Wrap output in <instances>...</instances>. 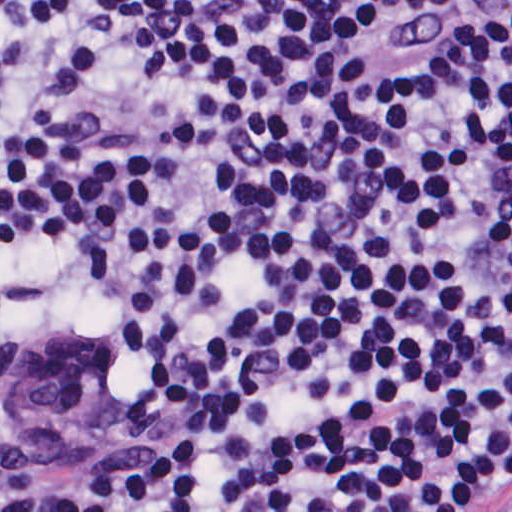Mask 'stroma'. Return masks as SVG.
Here are the masks:
<instances>
[{
	"mask_svg": "<svg viewBox=\"0 0 512 512\" xmlns=\"http://www.w3.org/2000/svg\"><path fill=\"white\" fill-rule=\"evenodd\" d=\"M9 340L28 348H38L0 324V464L33 453L23 446L10 408L1 396V349Z\"/></svg>",
	"mask_w": 512,
	"mask_h": 512,
	"instance_id": "35a3bbf8",
	"label": "stroma"
}]
</instances>
